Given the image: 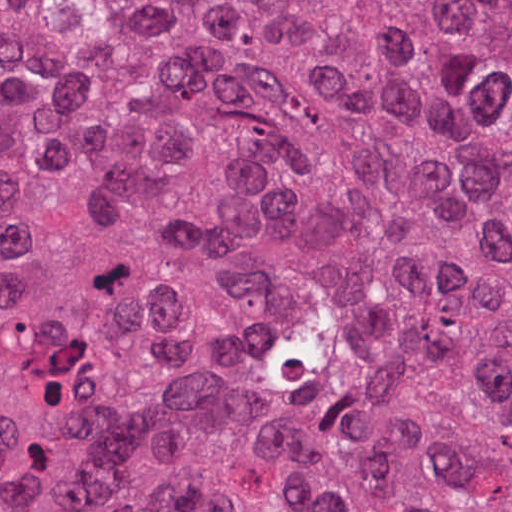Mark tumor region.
<instances>
[{"mask_svg": "<svg viewBox=\"0 0 512 512\" xmlns=\"http://www.w3.org/2000/svg\"><path fill=\"white\" fill-rule=\"evenodd\" d=\"M0 512H512V1H0Z\"/></svg>", "mask_w": 512, "mask_h": 512, "instance_id": "e687c5a6", "label": "tumor region"}]
</instances>
